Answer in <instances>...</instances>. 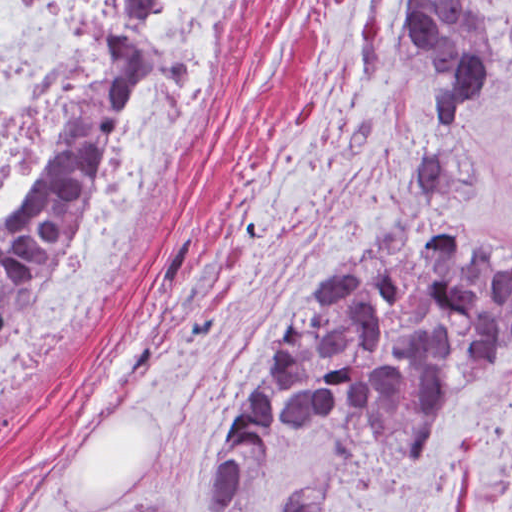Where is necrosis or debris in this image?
Instances as JSON below:
<instances>
[{"mask_svg":"<svg viewBox=\"0 0 512 512\" xmlns=\"http://www.w3.org/2000/svg\"><path fill=\"white\" fill-rule=\"evenodd\" d=\"M118 0H0V245L32 214L100 100ZM249 0H157L145 102L59 251L0 334V410L127 305L147 234Z\"/></svg>","mask_w":512,"mask_h":512,"instance_id":"obj_1","label":"necrosis or debris"}]
</instances>
